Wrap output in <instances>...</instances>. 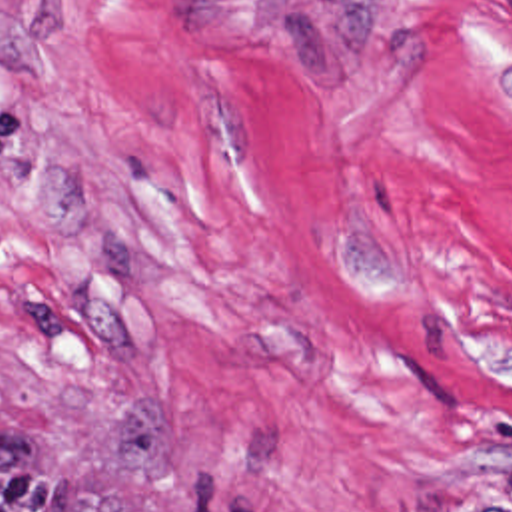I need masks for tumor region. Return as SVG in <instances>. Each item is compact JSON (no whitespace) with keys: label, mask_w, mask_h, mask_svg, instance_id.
I'll list each match as a JSON object with an SVG mask.
<instances>
[{"label":"tumor region","mask_w":512,"mask_h":512,"mask_svg":"<svg viewBox=\"0 0 512 512\" xmlns=\"http://www.w3.org/2000/svg\"><path fill=\"white\" fill-rule=\"evenodd\" d=\"M369 24V0H289V32L299 64L327 66L353 52ZM0 512H129L125 485H87L75 463L41 473L13 438H0ZM405 512H512V461L461 497H419Z\"/></svg>","instance_id":"tumor-region-1"}]
</instances>
